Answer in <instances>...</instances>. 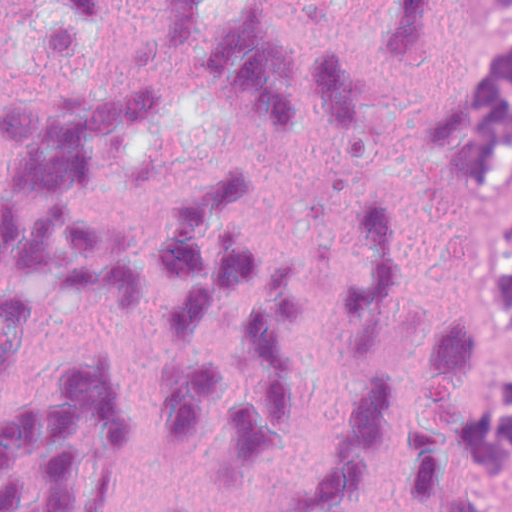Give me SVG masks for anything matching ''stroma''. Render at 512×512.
<instances>
[{"label": "stroma", "instance_id": "obj_1", "mask_svg": "<svg viewBox=\"0 0 512 512\" xmlns=\"http://www.w3.org/2000/svg\"><path fill=\"white\" fill-rule=\"evenodd\" d=\"M510 167L512 174V160ZM510 216H512V207ZM487 317L496 359L512 367V330L503 315L501 301L495 290L487 300ZM506 506L512 509V450Z\"/></svg>", "mask_w": 512, "mask_h": 512}]
</instances>
